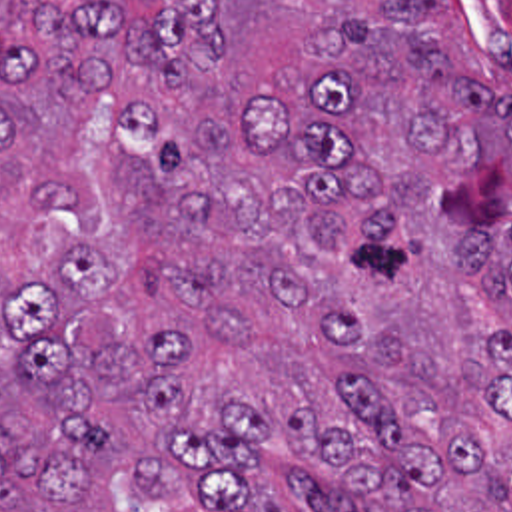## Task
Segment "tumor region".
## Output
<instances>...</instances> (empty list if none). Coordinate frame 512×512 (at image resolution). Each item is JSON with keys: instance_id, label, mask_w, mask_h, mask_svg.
Returning a JSON list of instances; mask_svg holds the SVG:
<instances>
[{"instance_id": "1", "label": "tumor region", "mask_w": 512, "mask_h": 512, "mask_svg": "<svg viewBox=\"0 0 512 512\" xmlns=\"http://www.w3.org/2000/svg\"><path fill=\"white\" fill-rule=\"evenodd\" d=\"M0 512H512L457 0H0Z\"/></svg>"}]
</instances>
